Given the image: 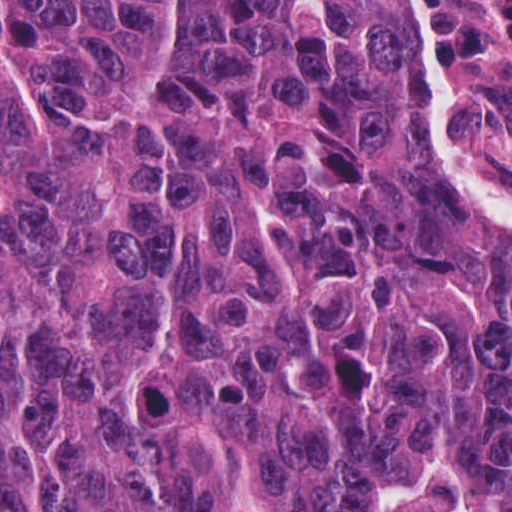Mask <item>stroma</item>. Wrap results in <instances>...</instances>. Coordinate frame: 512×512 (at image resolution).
I'll use <instances>...</instances> for the list:
<instances>
[{"label":"stroma","mask_w":512,"mask_h":512,"mask_svg":"<svg viewBox=\"0 0 512 512\" xmlns=\"http://www.w3.org/2000/svg\"><path fill=\"white\" fill-rule=\"evenodd\" d=\"M412 80L419 88L411 39L397 0ZM443 32L451 69L473 82H451L453 132L481 179L512 206V0H425ZM421 163L471 228L499 241L512 257V240L469 209L441 176L426 113Z\"/></svg>","instance_id":"1"}]
</instances>
